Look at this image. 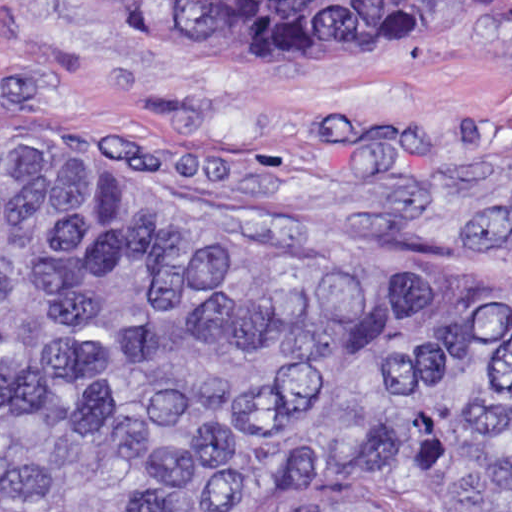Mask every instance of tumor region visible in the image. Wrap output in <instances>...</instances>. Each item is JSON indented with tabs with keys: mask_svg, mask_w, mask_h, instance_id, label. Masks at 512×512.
<instances>
[{
	"mask_svg": "<svg viewBox=\"0 0 512 512\" xmlns=\"http://www.w3.org/2000/svg\"><path fill=\"white\" fill-rule=\"evenodd\" d=\"M374 52L512 0H106ZM398 211L0 144V512H512V105L303 111Z\"/></svg>",
	"mask_w": 512,
	"mask_h": 512,
	"instance_id": "e687c5a6",
	"label": "tumor region"
}]
</instances>
